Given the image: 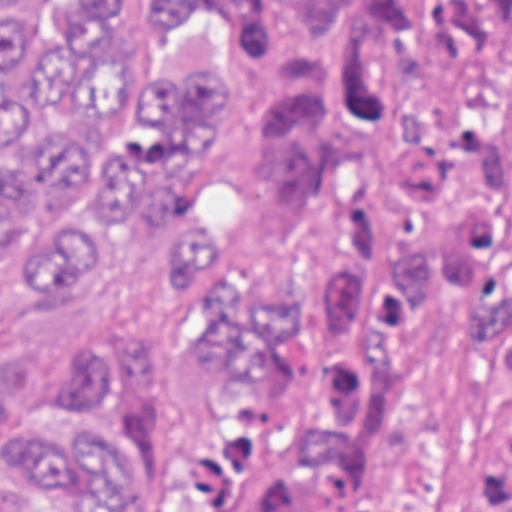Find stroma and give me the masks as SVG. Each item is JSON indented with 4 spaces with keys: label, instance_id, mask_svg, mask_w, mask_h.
<instances>
[{
    "label": "stroma",
    "instance_id": "35a3bbf8",
    "mask_svg": "<svg viewBox=\"0 0 512 512\" xmlns=\"http://www.w3.org/2000/svg\"><path fill=\"white\" fill-rule=\"evenodd\" d=\"M40 3L3 0L13 38ZM111 21L132 98L175 56H230L241 82L230 138L170 175L165 208L228 254L245 283L300 304L305 367L295 392H260L208 375L218 350L217 311L202 288L175 273V245L123 219H89L100 248L87 288L79 299L19 289L0 317V375L44 410L81 374L153 349L161 365L160 449L189 487L195 453L214 435L241 433L317 393L330 376V311L264 200L260 137L276 79L260 40L238 30L150 38L139 0H115ZM91 214L84 208L0 252V303L37 251ZM498 415L493 362L480 336L461 324L421 328L410 396L385 435L379 478L406 512H476V451ZM0 512H53L35 489L8 478L1 449Z\"/></svg>",
    "mask_w": 512,
    "mask_h": 512
}]
</instances>
